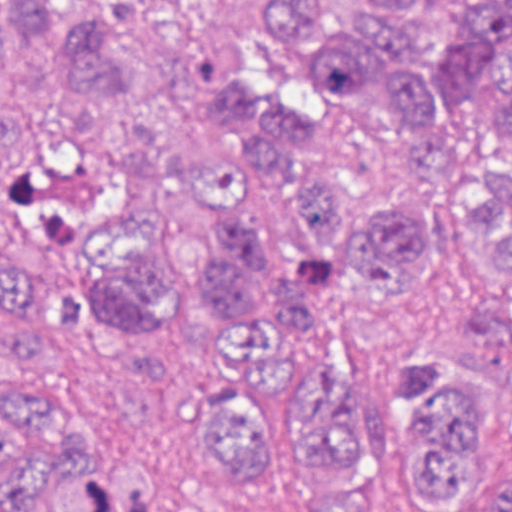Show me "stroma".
Listing matches in <instances>:
<instances>
[{
  "instance_id": "obj_1",
  "label": "stroma",
  "mask_w": 512,
  "mask_h": 512,
  "mask_svg": "<svg viewBox=\"0 0 512 512\" xmlns=\"http://www.w3.org/2000/svg\"><path fill=\"white\" fill-rule=\"evenodd\" d=\"M18 0H0L18 22L17 63L0 69V92L30 94L48 128L36 165L0 168L23 200L44 207L65 244L86 250L118 205L122 144L134 129L211 172H251L246 152L206 141L173 110L83 94L67 78V54L31 40ZM102 4V0H78ZM240 39L247 73L290 98L311 101L326 117L304 152L312 173L341 187L361 207L380 200L418 203L440 214L461 170H431L414 146L410 120L389 99H353L304 71L293 42L255 0H192ZM468 160L504 163L499 127ZM279 355L339 364L373 419L393 427L397 387L412 349L455 354L486 375L499 396V446L479 503L496 512L512 475V288L460 256H440L418 294L394 307H369L335 280L314 320L276 338ZM67 404L95 444L113 456L150 463L161 485L157 512H314L318 485L308 466L286 465L256 491L218 481L204 460V419L192 403L94 362L87 341L67 332L48 369H4ZM39 512H48L44 507ZM383 512H436L393 476Z\"/></svg>"
}]
</instances>
